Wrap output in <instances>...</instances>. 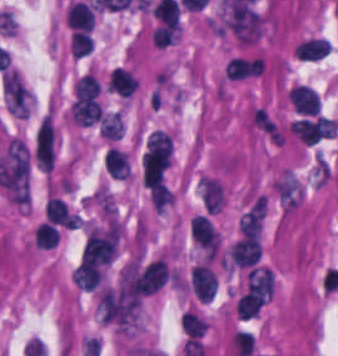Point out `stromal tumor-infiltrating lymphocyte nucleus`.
Here are the masks:
<instances>
[{"instance_id": "bc302bb0", "label": "stromal tumor-infiltrating lymphocyte nucleus", "mask_w": 338, "mask_h": 356, "mask_svg": "<svg viewBox=\"0 0 338 356\" xmlns=\"http://www.w3.org/2000/svg\"><path fill=\"white\" fill-rule=\"evenodd\" d=\"M185 288L201 302L210 301L218 291V279L210 262L198 261L190 267Z\"/></svg>"}, {"instance_id": "52c7bb5b", "label": "stromal tumor-infiltrating lymphocyte nucleus", "mask_w": 338, "mask_h": 356, "mask_svg": "<svg viewBox=\"0 0 338 356\" xmlns=\"http://www.w3.org/2000/svg\"><path fill=\"white\" fill-rule=\"evenodd\" d=\"M287 95L297 112L314 115L319 113V94L309 84L296 83L288 89Z\"/></svg>"}, {"instance_id": "3290ff9b", "label": "stromal tumor-infiltrating lymphocyte nucleus", "mask_w": 338, "mask_h": 356, "mask_svg": "<svg viewBox=\"0 0 338 356\" xmlns=\"http://www.w3.org/2000/svg\"><path fill=\"white\" fill-rule=\"evenodd\" d=\"M70 116L78 127H89L99 122L102 111L94 98L73 101L69 107Z\"/></svg>"}, {"instance_id": "abfb95fc", "label": "stromal tumor-infiltrating lymphocyte nucleus", "mask_w": 338, "mask_h": 356, "mask_svg": "<svg viewBox=\"0 0 338 356\" xmlns=\"http://www.w3.org/2000/svg\"><path fill=\"white\" fill-rule=\"evenodd\" d=\"M44 217L55 226L76 229V215L60 198L50 197L46 201L44 206Z\"/></svg>"}, {"instance_id": "9ea309e8", "label": "stromal tumor-infiltrating lymphocyte nucleus", "mask_w": 338, "mask_h": 356, "mask_svg": "<svg viewBox=\"0 0 338 356\" xmlns=\"http://www.w3.org/2000/svg\"><path fill=\"white\" fill-rule=\"evenodd\" d=\"M330 44L327 38L312 35L296 45L294 48L298 58L307 62H317L329 52Z\"/></svg>"}, {"instance_id": "f3e2335f", "label": "stromal tumor-infiltrating lymphocyte nucleus", "mask_w": 338, "mask_h": 356, "mask_svg": "<svg viewBox=\"0 0 338 356\" xmlns=\"http://www.w3.org/2000/svg\"><path fill=\"white\" fill-rule=\"evenodd\" d=\"M102 268L79 262L70 273V281L83 291H91L99 286Z\"/></svg>"}, {"instance_id": "4f13568d", "label": "stromal tumor-infiltrating lymphocyte nucleus", "mask_w": 338, "mask_h": 356, "mask_svg": "<svg viewBox=\"0 0 338 356\" xmlns=\"http://www.w3.org/2000/svg\"><path fill=\"white\" fill-rule=\"evenodd\" d=\"M136 81L129 69L114 67L109 73L108 89L123 97H131Z\"/></svg>"}, {"instance_id": "2a367800", "label": "stromal tumor-infiltrating lymphocyte nucleus", "mask_w": 338, "mask_h": 356, "mask_svg": "<svg viewBox=\"0 0 338 356\" xmlns=\"http://www.w3.org/2000/svg\"><path fill=\"white\" fill-rule=\"evenodd\" d=\"M103 164L106 170L115 178H129L130 165L123 151L108 147L104 152Z\"/></svg>"}, {"instance_id": "4803ca6d", "label": "stromal tumor-infiltrating lymphocyte nucleus", "mask_w": 338, "mask_h": 356, "mask_svg": "<svg viewBox=\"0 0 338 356\" xmlns=\"http://www.w3.org/2000/svg\"><path fill=\"white\" fill-rule=\"evenodd\" d=\"M263 304V300L248 288L237 300L236 315L248 321L258 316Z\"/></svg>"}, {"instance_id": "4245b91a", "label": "stromal tumor-infiltrating lymphocyte nucleus", "mask_w": 338, "mask_h": 356, "mask_svg": "<svg viewBox=\"0 0 338 356\" xmlns=\"http://www.w3.org/2000/svg\"><path fill=\"white\" fill-rule=\"evenodd\" d=\"M124 132V122L120 111L108 113L100 119L99 134L104 139H118Z\"/></svg>"}, {"instance_id": "4c9ddf68", "label": "stromal tumor-infiltrating lymphocyte nucleus", "mask_w": 338, "mask_h": 356, "mask_svg": "<svg viewBox=\"0 0 338 356\" xmlns=\"http://www.w3.org/2000/svg\"><path fill=\"white\" fill-rule=\"evenodd\" d=\"M180 328L185 336L198 339L206 330L205 322L191 311H183L179 318Z\"/></svg>"}, {"instance_id": "2761f720", "label": "stromal tumor-infiltrating lymphocyte nucleus", "mask_w": 338, "mask_h": 356, "mask_svg": "<svg viewBox=\"0 0 338 356\" xmlns=\"http://www.w3.org/2000/svg\"><path fill=\"white\" fill-rule=\"evenodd\" d=\"M178 32L179 22L175 19L165 22L155 28L150 35V39L154 44L164 48L174 44Z\"/></svg>"}, {"instance_id": "3c572f05", "label": "stromal tumor-infiltrating lymphocyte nucleus", "mask_w": 338, "mask_h": 356, "mask_svg": "<svg viewBox=\"0 0 338 356\" xmlns=\"http://www.w3.org/2000/svg\"><path fill=\"white\" fill-rule=\"evenodd\" d=\"M59 234L55 225L48 222L39 223L33 232V243L38 248H51L56 246Z\"/></svg>"}, {"instance_id": "42bb06b2", "label": "stromal tumor-infiltrating lymphocyte nucleus", "mask_w": 338, "mask_h": 356, "mask_svg": "<svg viewBox=\"0 0 338 356\" xmlns=\"http://www.w3.org/2000/svg\"><path fill=\"white\" fill-rule=\"evenodd\" d=\"M92 38L90 34L80 30L73 29L70 32L69 49L74 58H82L91 53Z\"/></svg>"}, {"instance_id": "9e4306bb", "label": "stromal tumor-infiltrating lymphocyte nucleus", "mask_w": 338, "mask_h": 356, "mask_svg": "<svg viewBox=\"0 0 338 356\" xmlns=\"http://www.w3.org/2000/svg\"><path fill=\"white\" fill-rule=\"evenodd\" d=\"M100 86L88 72L80 76L74 84L75 98L80 102L92 98H96Z\"/></svg>"}]
</instances>
